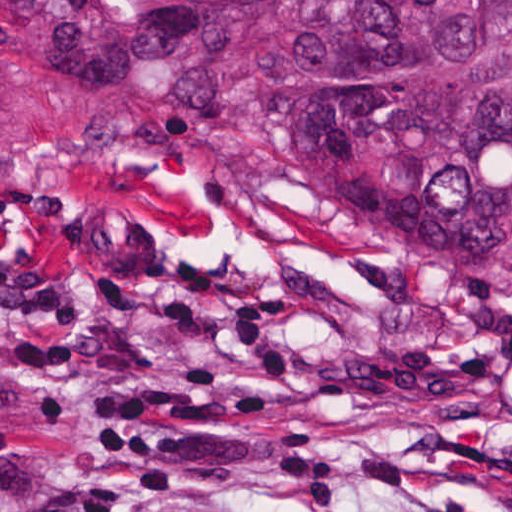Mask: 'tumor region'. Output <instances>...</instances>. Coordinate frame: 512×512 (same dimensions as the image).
I'll return each mask as SVG.
<instances>
[{
    "mask_svg": "<svg viewBox=\"0 0 512 512\" xmlns=\"http://www.w3.org/2000/svg\"><path fill=\"white\" fill-rule=\"evenodd\" d=\"M0 112L96 140L185 200L367 243L512 320V0H0ZM0 302L101 310L0 223Z\"/></svg>",
    "mask_w": 512,
    "mask_h": 512,
    "instance_id": "e687c5a6",
    "label": "tumor region"
}]
</instances>
